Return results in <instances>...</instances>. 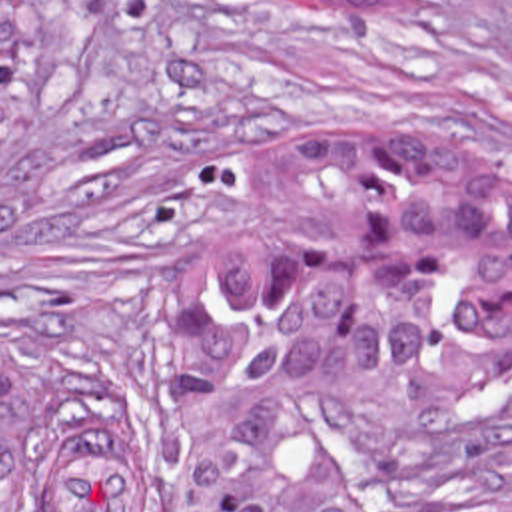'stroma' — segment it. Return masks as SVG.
I'll list each match as a JSON object with an SVG mask.
<instances>
[{
  "label": "stroma",
  "instance_id": "stroma-1",
  "mask_svg": "<svg viewBox=\"0 0 512 512\" xmlns=\"http://www.w3.org/2000/svg\"><path fill=\"white\" fill-rule=\"evenodd\" d=\"M373 125L470 131L512 197V0H39L0 139V347L133 411L145 512H175L177 317L265 241L261 157ZM361 431L510 441L512 387L375 391Z\"/></svg>",
  "mask_w": 512,
  "mask_h": 512
}]
</instances>
